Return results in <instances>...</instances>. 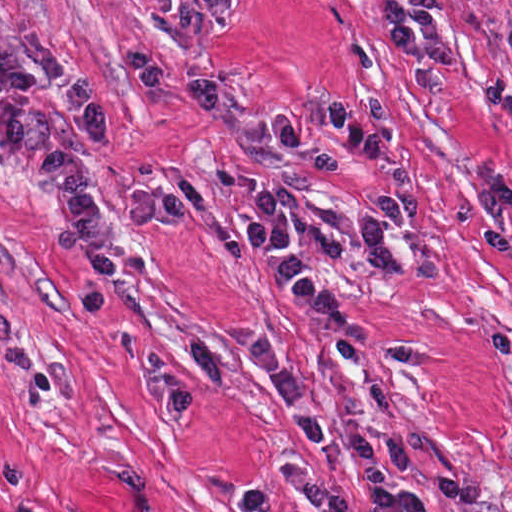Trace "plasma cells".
Masks as SVG:
<instances>
[{
    "label": "plasma cells",
    "mask_w": 512,
    "mask_h": 512,
    "mask_svg": "<svg viewBox=\"0 0 512 512\" xmlns=\"http://www.w3.org/2000/svg\"><path fill=\"white\" fill-rule=\"evenodd\" d=\"M158 14L166 35L188 48L205 43L224 21L230 0H136ZM126 70L147 92H160L197 115L221 112V82L207 76L179 84L166 63L135 46H121ZM50 88L45 96H0V153L22 159L32 169L57 219L52 250L78 259L91 269L81 290L90 313L104 316L114 280L144 275L141 256L123 253L125 229H181L187 222V200L168 188L128 193L123 207L100 214L94 191L65 132L50 123L44 109L57 104L95 145L110 142L106 102L76 58L42 35L25 36L16 48L0 44V93ZM393 184L376 198L366 223L340 207L317 201H295L290 222L295 232L320 253L382 278H411L424 284H446V266L434 245L420 243L408 253L393 237L416 228L419 199L410 163L380 153L370 161ZM281 397L298 431L321 456L347 464L359 476L372 512H427L424 495L408 478H416L449 504L472 506L487 501L485 489L431 468L432 446L420 433L405 435L395 403L374 380L373 365L416 367L427 362L422 347L373 350L340 340L335 344L344 368L355 374L373 396L381 431L377 454L359 424L351 397L341 400L347 436L340 433L326 404L312 393L292 358L266 332L242 333L238 339ZM117 352L129 367L149 373L155 402L167 426L188 424L202 405V387L189 380L153 342L120 330ZM289 488L313 512H356L340 485L313 473L290 468Z\"/></svg>",
    "instance_id": "1"
}]
</instances>
